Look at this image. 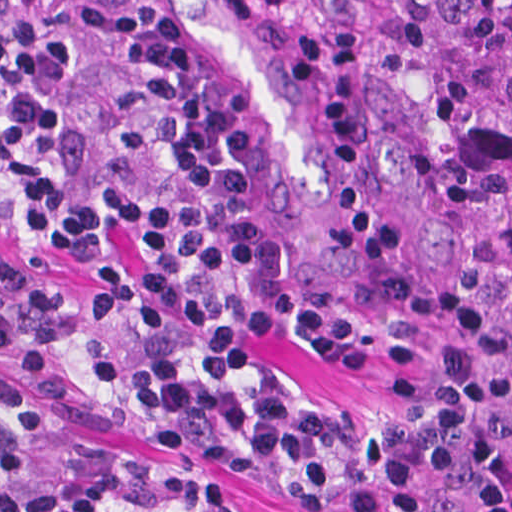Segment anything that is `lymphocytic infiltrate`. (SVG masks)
<instances>
[{"instance_id":"f902f5d3","label":"lymphocytic infiltrate","mask_w":512,"mask_h":512,"mask_svg":"<svg viewBox=\"0 0 512 512\" xmlns=\"http://www.w3.org/2000/svg\"><path fill=\"white\" fill-rule=\"evenodd\" d=\"M0 350L54 406L274 489L290 512H512V370L456 289L339 293L264 214L238 114L159 0H0ZM273 343L362 374V421L310 405ZM0 512H244L203 473L120 461L0 386Z\"/></svg>"}]
</instances>
